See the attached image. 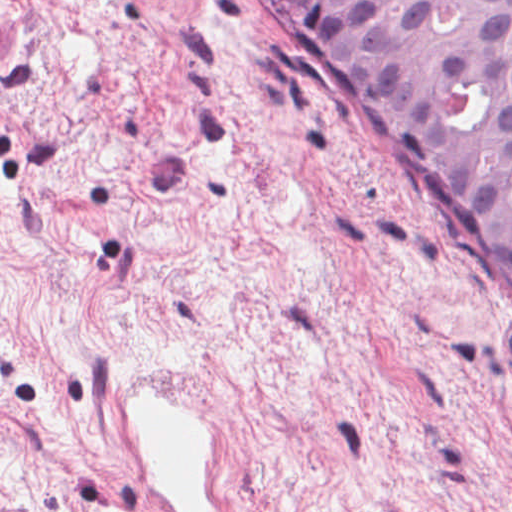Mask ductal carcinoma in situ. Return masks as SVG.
<instances>
[{
	"instance_id": "ductal-carcinoma-in-situ-1",
	"label": "ductal carcinoma in situ",
	"mask_w": 512,
	"mask_h": 512,
	"mask_svg": "<svg viewBox=\"0 0 512 512\" xmlns=\"http://www.w3.org/2000/svg\"><path fill=\"white\" fill-rule=\"evenodd\" d=\"M512 327V0H274Z\"/></svg>"
}]
</instances>
